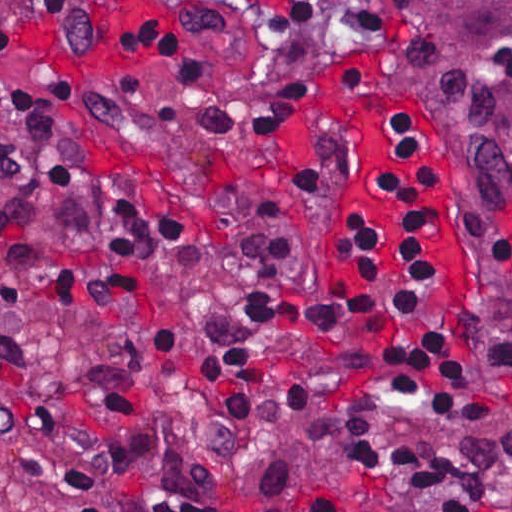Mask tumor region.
<instances>
[{
	"instance_id": "e687c5a6",
	"label": "tumor region",
	"mask_w": 512,
	"mask_h": 512,
	"mask_svg": "<svg viewBox=\"0 0 512 512\" xmlns=\"http://www.w3.org/2000/svg\"><path fill=\"white\" fill-rule=\"evenodd\" d=\"M359 16L386 113L466 208L481 405L450 421L405 405L310 410L243 480L271 499L355 490L387 512H512V0H359Z\"/></svg>"
}]
</instances>
